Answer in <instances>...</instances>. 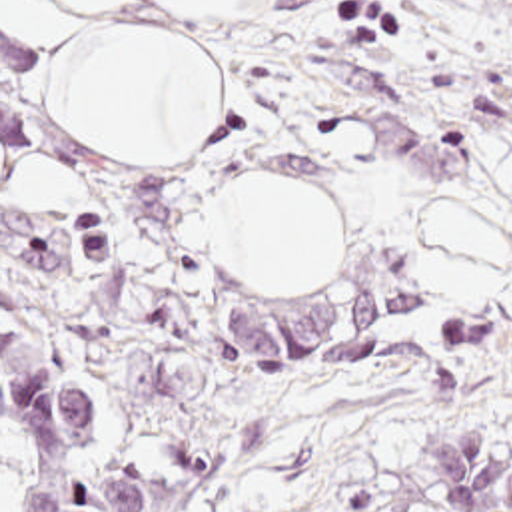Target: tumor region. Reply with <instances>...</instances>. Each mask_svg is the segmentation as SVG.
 <instances>
[{
    "label": "tumor region",
    "instance_id": "1",
    "mask_svg": "<svg viewBox=\"0 0 512 512\" xmlns=\"http://www.w3.org/2000/svg\"><path fill=\"white\" fill-rule=\"evenodd\" d=\"M393 279H373L291 301L230 305L222 323L254 373L323 377L385 359L391 363L383 299ZM451 349H475L501 325L439 319ZM413 478L433 512H512V438L501 426L451 420L421 428Z\"/></svg>",
    "mask_w": 512,
    "mask_h": 512
}]
</instances>
